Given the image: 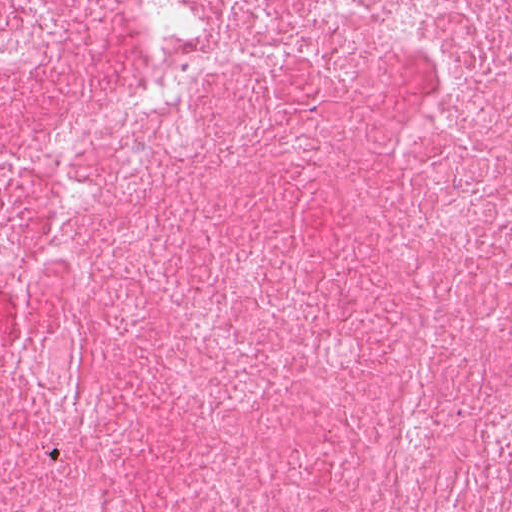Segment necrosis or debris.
I'll return each mask as SVG.
<instances>
[{
	"label": "necrosis or debris",
	"instance_id": "obj_1",
	"mask_svg": "<svg viewBox=\"0 0 512 512\" xmlns=\"http://www.w3.org/2000/svg\"><path fill=\"white\" fill-rule=\"evenodd\" d=\"M0 512H512V0H0Z\"/></svg>",
	"mask_w": 512,
	"mask_h": 512
}]
</instances>
